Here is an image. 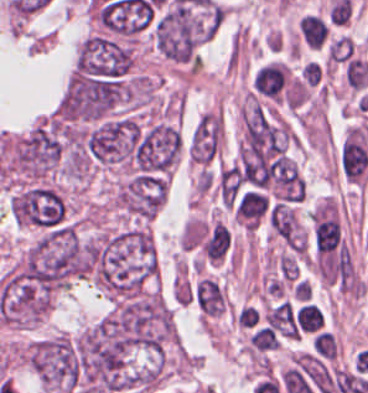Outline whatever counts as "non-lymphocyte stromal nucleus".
I'll return each instance as SVG.
<instances>
[{
    "label": "non-lymphocyte stromal nucleus",
    "instance_id": "obj_1",
    "mask_svg": "<svg viewBox=\"0 0 368 393\" xmlns=\"http://www.w3.org/2000/svg\"><path fill=\"white\" fill-rule=\"evenodd\" d=\"M222 141V119L217 113L200 116L190 135L189 157L192 160H211Z\"/></svg>",
    "mask_w": 368,
    "mask_h": 393
}]
</instances>
